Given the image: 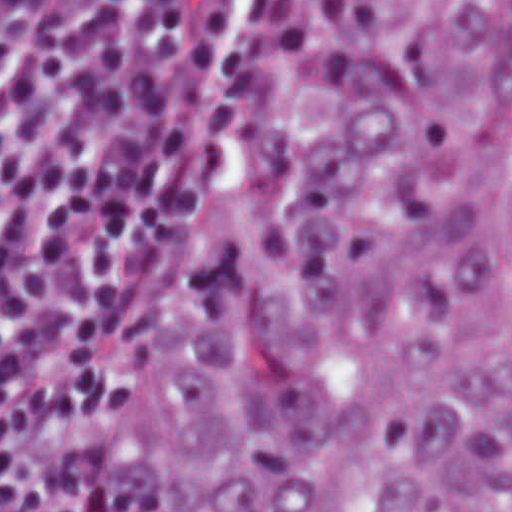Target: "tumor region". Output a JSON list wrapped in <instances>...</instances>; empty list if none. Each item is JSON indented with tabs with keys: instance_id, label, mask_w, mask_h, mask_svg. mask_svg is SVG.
<instances>
[{
	"instance_id": "tumor-region-1",
	"label": "tumor region",
	"mask_w": 512,
	"mask_h": 512,
	"mask_svg": "<svg viewBox=\"0 0 512 512\" xmlns=\"http://www.w3.org/2000/svg\"><path fill=\"white\" fill-rule=\"evenodd\" d=\"M119 512H512V1H331L205 166Z\"/></svg>"
}]
</instances>
